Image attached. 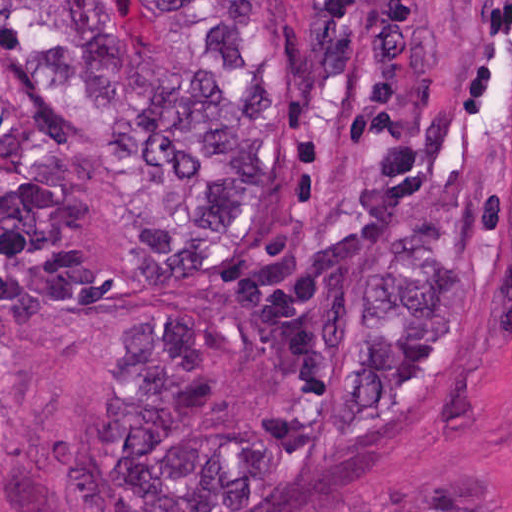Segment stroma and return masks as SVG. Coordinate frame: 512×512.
<instances>
[{"instance_id": "obj_1", "label": "stroma", "mask_w": 512, "mask_h": 512, "mask_svg": "<svg viewBox=\"0 0 512 512\" xmlns=\"http://www.w3.org/2000/svg\"><path fill=\"white\" fill-rule=\"evenodd\" d=\"M106 1L143 45L161 50L151 1ZM159 313L146 301L102 316L55 314L18 344H0V512H149L82 480L84 441L109 400L115 331ZM481 501L512 512V187L503 205L494 336L457 401L364 471L278 512H427Z\"/></svg>"}]
</instances>
